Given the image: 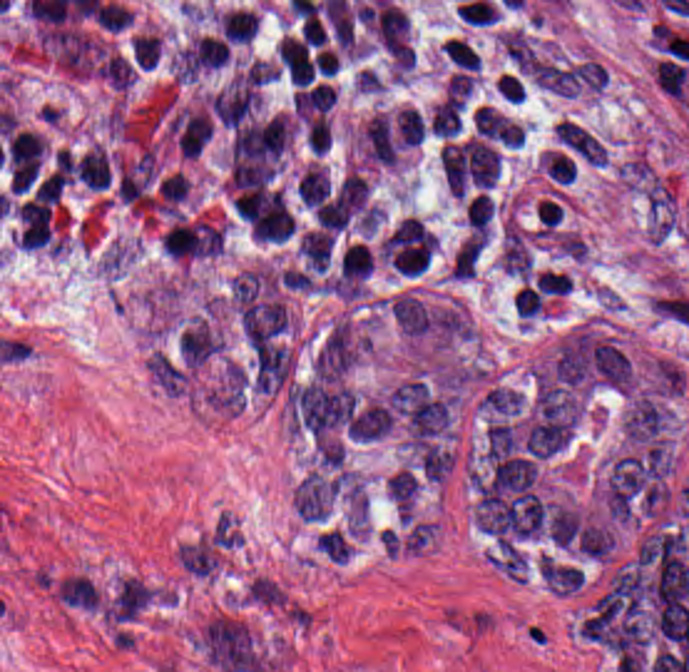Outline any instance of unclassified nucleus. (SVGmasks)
<instances>
[{
	"mask_svg": "<svg viewBox=\"0 0 689 672\" xmlns=\"http://www.w3.org/2000/svg\"><path fill=\"white\" fill-rule=\"evenodd\" d=\"M358 348L351 320L338 317L313 356L315 371L338 377L356 361Z\"/></svg>",
	"mask_w": 689,
	"mask_h": 672,
	"instance_id": "0b8be0a9",
	"label": "unclassified nucleus"
},
{
	"mask_svg": "<svg viewBox=\"0 0 689 672\" xmlns=\"http://www.w3.org/2000/svg\"><path fill=\"white\" fill-rule=\"evenodd\" d=\"M339 484L307 470L294 487L290 503L298 518L322 519Z\"/></svg>",
	"mask_w": 689,
	"mask_h": 672,
	"instance_id": "b2318f4d",
	"label": "unclassified nucleus"
}]
</instances>
